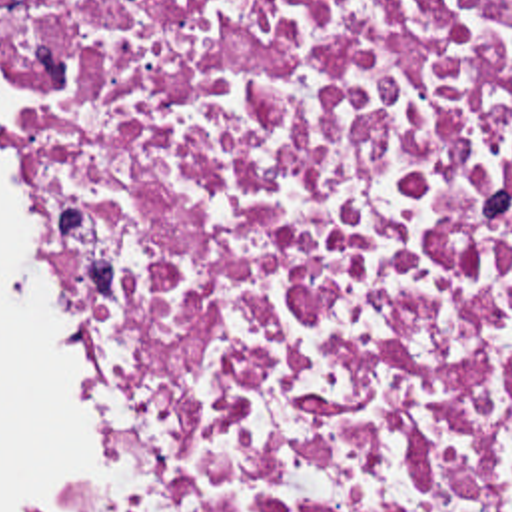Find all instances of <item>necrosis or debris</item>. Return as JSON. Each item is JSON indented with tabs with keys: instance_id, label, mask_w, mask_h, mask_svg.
Wrapping results in <instances>:
<instances>
[{
	"instance_id": "4bbe7bcc",
	"label": "necrosis or debris",
	"mask_w": 512,
	"mask_h": 512,
	"mask_svg": "<svg viewBox=\"0 0 512 512\" xmlns=\"http://www.w3.org/2000/svg\"><path fill=\"white\" fill-rule=\"evenodd\" d=\"M95 468L11 512H512V0H0Z\"/></svg>"
}]
</instances>
